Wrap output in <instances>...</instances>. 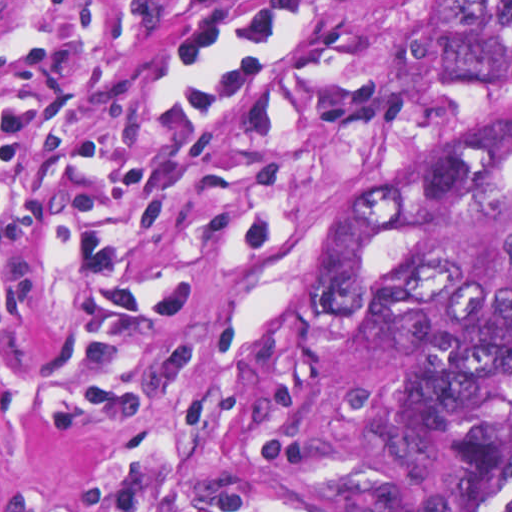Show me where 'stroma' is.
Segmentation results:
<instances>
[{
	"label": "stroma",
	"mask_w": 512,
	"mask_h": 512,
	"mask_svg": "<svg viewBox=\"0 0 512 512\" xmlns=\"http://www.w3.org/2000/svg\"><path fill=\"white\" fill-rule=\"evenodd\" d=\"M442 1L512 0H0V512H197L305 242L397 177Z\"/></svg>",
	"instance_id": "stroma-1"
}]
</instances>
